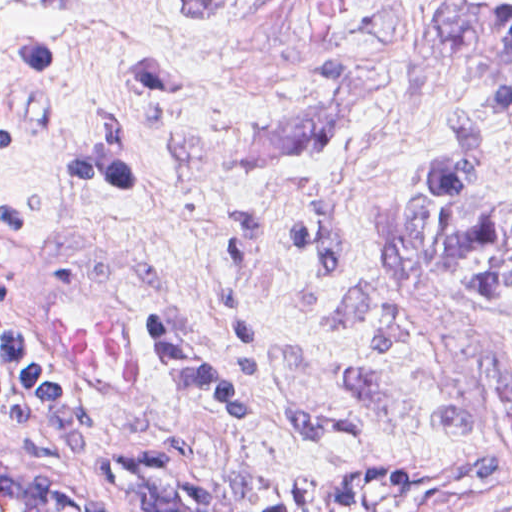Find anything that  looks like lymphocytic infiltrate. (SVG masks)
Listing matches in <instances>:
<instances>
[{
	"label": "lymphocytic infiltrate",
	"mask_w": 512,
	"mask_h": 512,
	"mask_svg": "<svg viewBox=\"0 0 512 512\" xmlns=\"http://www.w3.org/2000/svg\"><path fill=\"white\" fill-rule=\"evenodd\" d=\"M8 31V30H7ZM12 56L22 72L66 66L31 41L10 31ZM18 145L15 135L0 123V154ZM64 177L87 189L127 198L130 191L114 158L97 131L82 146L62 156ZM38 212L0 197V231L32 230ZM261 245V220L244 216L230 229L218 276V291L233 325L240 356L239 377L211 365L187 338L179 322L153 310L145 326L161 345L173 368L201 385L236 429L250 426L259 384L256 346L243 323V285ZM0 414L21 432L59 447H82L94 435L91 421L42 350L21 330L1 297L0 270Z\"/></svg>",
	"instance_id": "1"
}]
</instances>
